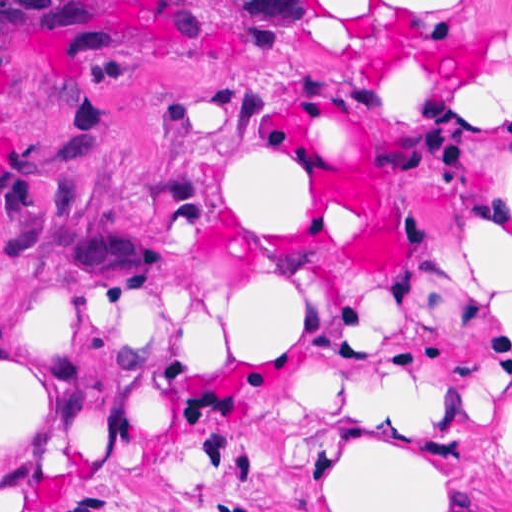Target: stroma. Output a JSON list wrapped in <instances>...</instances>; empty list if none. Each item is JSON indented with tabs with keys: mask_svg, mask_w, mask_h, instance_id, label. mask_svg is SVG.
Listing matches in <instances>:
<instances>
[{
	"mask_svg": "<svg viewBox=\"0 0 512 512\" xmlns=\"http://www.w3.org/2000/svg\"><path fill=\"white\" fill-rule=\"evenodd\" d=\"M93 1L104 56L24 37L0 92V282L88 308H183L223 261L286 248L315 265L328 327L402 339L469 327L512 400V330L456 252L450 122L512 107L458 75L382 56L328 1ZM512 54L506 37L489 82ZM247 163L304 187L299 247L236 218ZM206 291V292H205ZM450 485L438 512H512V466L481 443L361 407H276L165 450L86 468L39 512H316L323 447L345 431Z\"/></svg>",
	"mask_w": 512,
	"mask_h": 512,
	"instance_id": "1",
	"label": "stroma"
}]
</instances>
